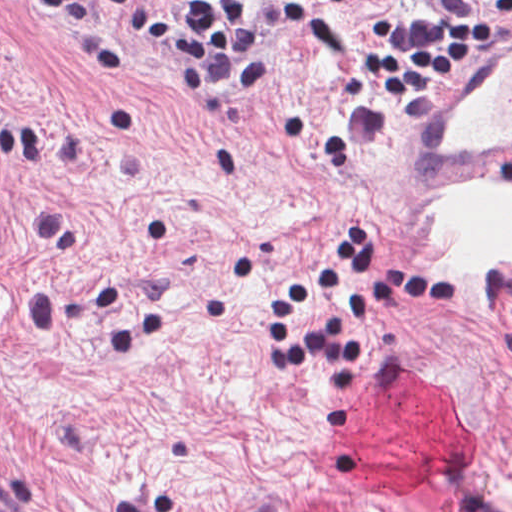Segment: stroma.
Segmentation results:
<instances>
[{"label": "stroma", "mask_w": 512, "mask_h": 512, "mask_svg": "<svg viewBox=\"0 0 512 512\" xmlns=\"http://www.w3.org/2000/svg\"><path fill=\"white\" fill-rule=\"evenodd\" d=\"M415 16L495 34L431 94L347 102L374 23ZM267 63L202 120L119 18L0 7V512H512V266L356 315L353 366L272 369L266 316L348 228L378 276L298 334L391 268L433 274L434 198L512 193V142L435 137L512 68V13L271 0Z\"/></svg>", "instance_id": "obj_1"}]
</instances>
